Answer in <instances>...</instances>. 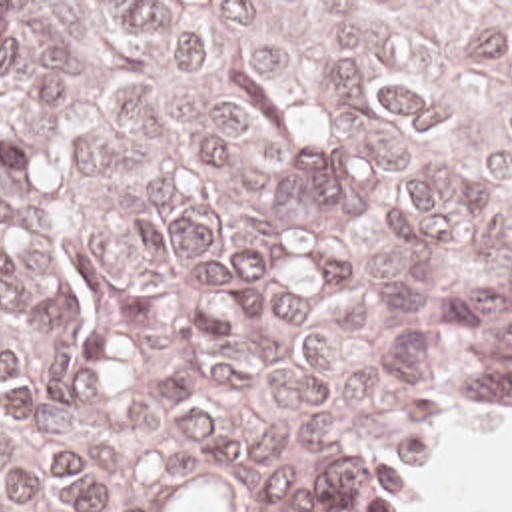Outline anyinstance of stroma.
Here are the masks:
<instances>
[{"label":"stroma","mask_w":512,"mask_h":512,"mask_svg":"<svg viewBox=\"0 0 512 512\" xmlns=\"http://www.w3.org/2000/svg\"><path fill=\"white\" fill-rule=\"evenodd\" d=\"M0 2H512V0H0ZM496 411H512V403H490V405H478V407H468L464 411H458L446 417L424 439L404 449L394 469L378 483L368 512H396L412 471L416 469V465L422 461L428 447L436 441V437L442 431L462 421L492 415Z\"/></svg>","instance_id":"obj_1"}]
</instances>
